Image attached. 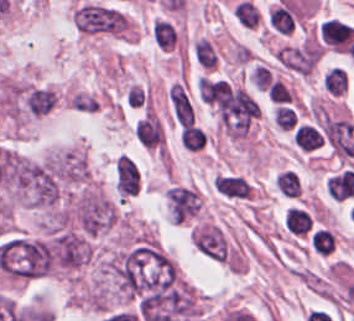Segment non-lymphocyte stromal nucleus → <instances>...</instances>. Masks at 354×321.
I'll return each instance as SVG.
<instances>
[{
	"instance_id": "81446118",
	"label": "non-lymphocyte stromal nucleus",
	"mask_w": 354,
	"mask_h": 321,
	"mask_svg": "<svg viewBox=\"0 0 354 321\" xmlns=\"http://www.w3.org/2000/svg\"><path fill=\"white\" fill-rule=\"evenodd\" d=\"M194 54L205 68H214V52L205 38L200 37L194 42Z\"/></svg>"
},
{
	"instance_id": "a72fc3eb",
	"label": "non-lymphocyte stromal nucleus",
	"mask_w": 354,
	"mask_h": 321,
	"mask_svg": "<svg viewBox=\"0 0 354 321\" xmlns=\"http://www.w3.org/2000/svg\"><path fill=\"white\" fill-rule=\"evenodd\" d=\"M141 173L139 166L127 154H120L115 162V185L121 198L139 192Z\"/></svg>"
},
{
	"instance_id": "fc2b8d12",
	"label": "non-lymphocyte stromal nucleus",
	"mask_w": 354,
	"mask_h": 321,
	"mask_svg": "<svg viewBox=\"0 0 354 321\" xmlns=\"http://www.w3.org/2000/svg\"><path fill=\"white\" fill-rule=\"evenodd\" d=\"M172 218L183 222L198 212L200 205L195 191L185 187L172 186L167 190Z\"/></svg>"
},
{
	"instance_id": "3746e769",
	"label": "non-lymphocyte stromal nucleus",
	"mask_w": 354,
	"mask_h": 321,
	"mask_svg": "<svg viewBox=\"0 0 354 321\" xmlns=\"http://www.w3.org/2000/svg\"><path fill=\"white\" fill-rule=\"evenodd\" d=\"M168 102L172 115L179 125L194 124V104L184 85L176 82L168 88Z\"/></svg>"
},
{
	"instance_id": "dd21d789",
	"label": "non-lymphocyte stromal nucleus",
	"mask_w": 354,
	"mask_h": 321,
	"mask_svg": "<svg viewBox=\"0 0 354 321\" xmlns=\"http://www.w3.org/2000/svg\"><path fill=\"white\" fill-rule=\"evenodd\" d=\"M78 29L88 33H120L127 31L128 18L115 7L101 2H81L74 10Z\"/></svg>"
}]
</instances>
